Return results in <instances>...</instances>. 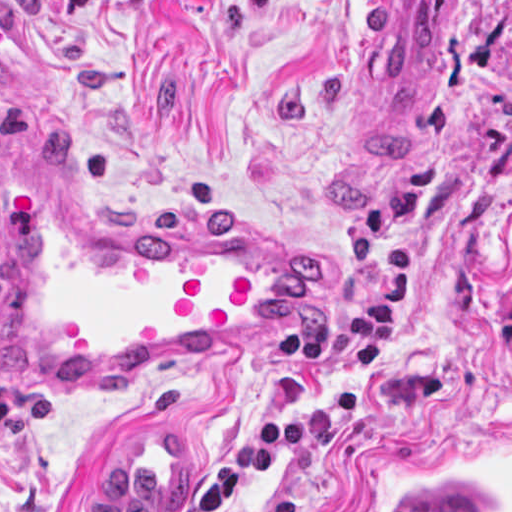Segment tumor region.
<instances>
[{"instance_id":"e687c5a6","label":"tumor region","mask_w":512,"mask_h":512,"mask_svg":"<svg viewBox=\"0 0 512 512\" xmlns=\"http://www.w3.org/2000/svg\"><path fill=\"white\" fill-rule=\"evenodd\" d=\"M386 512H487L481 503L466 499H440Z\"/></svg>"}]
</instances>
